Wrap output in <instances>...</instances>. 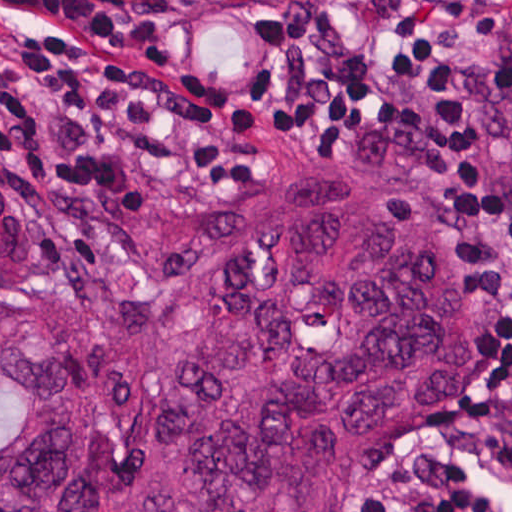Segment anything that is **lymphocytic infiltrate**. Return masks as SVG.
<instances>
[{"mask_svg": "<svg viewBox=\"0 0 512 512\" xmlns=\"http://www.w3.org/2000/svg\"><path fill=\"white\" fill-rule=\"evenodd\" d=\"M364 35L132 0H0V170L103 204L225 194L259 162L171 100L289 148L363 151L459 208L486 256L493 383L512 386V276L449 27ZM367 512H512V414Z\"/></svg>", "mask_w": 512, "mask_h": 512, "instance_id": "1", "label": "lymphocytic infiltrate"}]
</instances>
